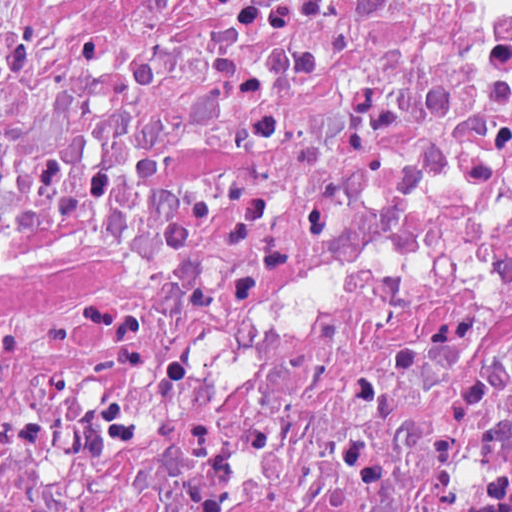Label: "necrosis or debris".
Segmentation results:
<instances>
[{
  "mask_svg": "<svg viewBox=\"0 0 512 512\" xmlns=\"http://www.w3.org/2000/svg\"><path fill=\"white\" fill-rule=\"evenodd\" d=\"M0 512H512V1H0Z\"/></svg>",
  "mask_w": 512,
  "mask_h": 512,
  "instance_id": "necrosis-or-debris-1",
  "label": "necrosis or debris"
}]
</instances>
